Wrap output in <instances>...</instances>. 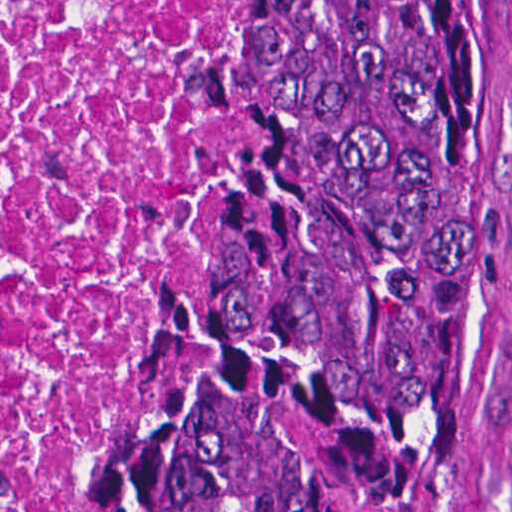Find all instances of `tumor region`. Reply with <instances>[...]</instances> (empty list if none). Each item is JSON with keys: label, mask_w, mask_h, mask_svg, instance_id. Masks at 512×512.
Masks as SVG:
<instances>
[{"label": "tumor region", "mask_w": 512, "mask_h": 512, "mask_svg": "<svg viewBox=\"0 0 512 512\" xmlns=\"http://www.w3.org/2000/svg\"><path fill=\"white\" fill-rule=\"evenodd\" d=\"M481 0H245L237 126L62 512H506Z\"/></svg>", "instance_id": "e687c5a6"}]
</instances>
